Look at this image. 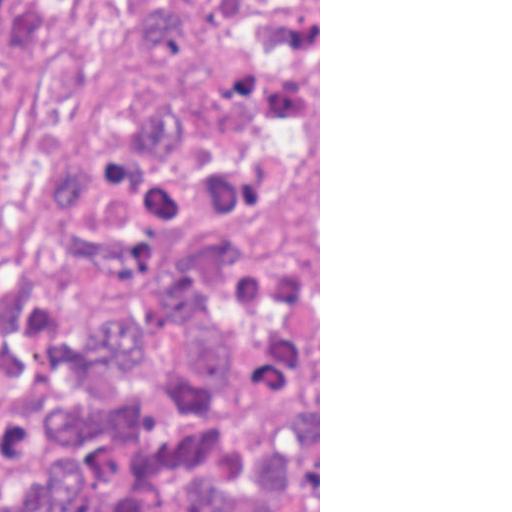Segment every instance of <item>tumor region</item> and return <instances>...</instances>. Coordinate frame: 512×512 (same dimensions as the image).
I'll list each match as a JSON object with an SVG mask.
<instances>
[{
	"label": "tumor region",
	"instance_id": "obj_1",
	"mask_svg": "<svg viewBox=\"0 0 512 512\" xmlns=\"http://www.w3.org/2000/svg\"><path fill=\"white\" fill-rule=\"evenodd\" d=\"M0 512H319L318 0H0Z\"/></svg>",
	"mask_w": 512,
	"mask_h": 512
}]
</instances>
